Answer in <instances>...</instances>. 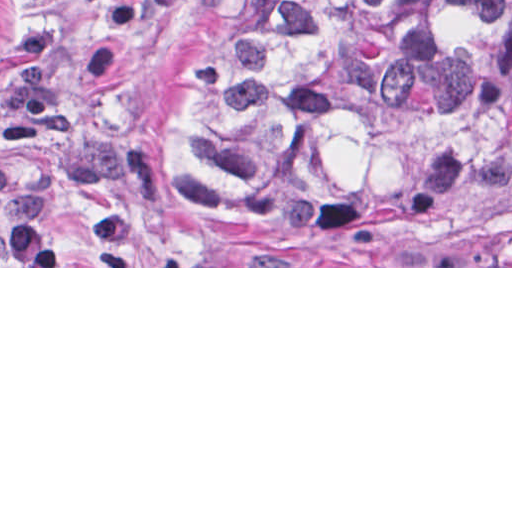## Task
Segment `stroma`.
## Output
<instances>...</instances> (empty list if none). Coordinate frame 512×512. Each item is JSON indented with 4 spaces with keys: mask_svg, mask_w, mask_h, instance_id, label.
I'll return each mask as SVG.
<instances>
[{
    "mask_svg": "<svg viewBox=\"0 0 512 512\" xmlns=\"http://www.w3.org/2000/svg\"><path fill=\"white\" fill-rule=\"evenodd\" d=\"M232 0H0V268H512V146L440 209L445 266H284L223 238L187 150Z\"/></svg>",
    "mask_w": 512,
    "mask_h": 512,
    "instance_id": "obj_1",
    "label": "stroma"
}]
</instances>
